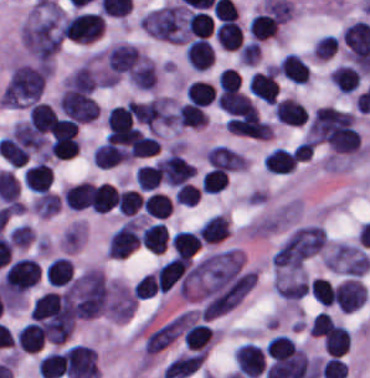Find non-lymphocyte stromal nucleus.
Returning <instances> with one entry per match:
<instances>
[{"instance_id":"dd21d789","label":"non-lymphocyte stromal nucleus","mask_w":370,"mask_h":378,"mask_svg":"<svg viewBox=\"0 0 370 378\" xmlns=\"http://www.w3.org/2000/svg\"><path fill=\"white\" fill-rule=\"evenodd\" d=\"M62 11L59 4L38 3L28 14L20 35L25 50L37 60H49L61 45Z\"/></svg>"},{"instance_id":"a72fc3eb","label":"non-lymphocyte stromal nucleus","mask_w":370,"mask_h":378,"mask_svg":"<svg viewBox=\"0 0 370 378\" xmlns=\"http://www.w3.org/2000/svg\"><path fill=\"white\" fill-rule=\"evenodd\" d=\"M326 244V235L319 225H302L291 230L278 246L273 265L276 269L297 270Z\"/></svg>"},{"instance_id":"3746e769","label":"non-lymphocyte stromal nucleus","mask_w":370,"mask_h":378,"mask_svg":"<svg viewBox=\"0 0 370 378\" xmlns=\"http://www.w3.org/2000/svg\"><path fill=\"white\" fill-rule=\"evenodd\" d=\"M45 72L39 64L20 63L9 72L1 106H30L39 100Z\"/></svg>"},{"instance_id":"fc2b8d12","label":"non-lymphocyte stromal nucleus","mask_w":370,"mask_h":378,"mask_svg":"<svg viewBox=\"0 0 370 378\" xmlns=\"http://www.w3.org/2000/svg\"><path fill=\"white\" fill-rule=\"evenodd\" d=\"M322 260L327 270L350 277H361L370 265V255L361 247L341 241L330 243Z\"/></svg>"},{"instance_id":"81446118","label":"non-lymphocyte stromal nucleus","mask_w":370,"mask_h":378,"mask_svg":"<svg viewBox=\"0 0 370 378\" xmlns=\"http://www.w3.org/2000/svg\"><path fill=\"white\" fill-rule=\"evenodd\" d=\"M59 108L60 112L81 123H90L98 115L91 95L74 87H66L61 92Z\"/></svg>"},{"instance_id":"7c5642bf","label":"non-lymphocyte stromal nucleus","mask_w":370,"mask_h":378,"mask_svg":"<svg viewBox=\"0 0 370 378\" xmlns=\"http://www.w3.org/2000/svg\"><path fill=\"white\" fill-rule=\"evenodd\" d=\"M271 282L276 296L286 302H297L308 292L301 271L276 270Z\"/></svg>"},{"instance_id":"9d01c50a","label":"non-lymphocyte stromal nucleus","mask_w":370,"mask_h":378,"mask_svg":"<svg viewBox=\"0 0 370 378\" xmlns=\"http://www.w3.org/2000/svg\"><path fill=\"white\" fill-rule=\"evenodd\" d=\"M204 155L208 163L214 167L233 172L248 168V161L243 153L221 145L208 147Z\"/></svg>"},{"instance_id":"2ac0efb1","label":"non-lymphocyte stromal nucleus","mask_w":370,"mask_h":378,"mask_svg":"<svg viewBox=\"0 0 370 378\" xmlns=\"http://www.w3.org/2000/svg\"><path fill=\"white\" fill-rule=\"evenodd\" d=\"M98 82L97 74L86 63L80 65L63 81L64 88L93 91Z\"/></svg>"},{"instance_id":"616ff342","label":"non-lymphocyte stromal nucleus","mask_w":370,"mask_h":378,"mask_svg":"<svg viewBox=\"0 0 370 378\" xmlns=\"http://www.w3.org/2000/svg\"><path fill=\"white\" fill-rule=\"evenodd\" d=\"M32 208L42 218H49L60 210V199L54 192H40L32 202Z\"/></svg>"}]
</instances>
